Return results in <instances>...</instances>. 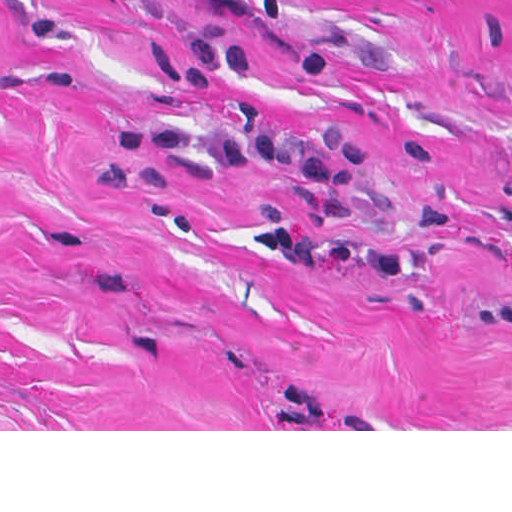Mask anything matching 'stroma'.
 <instances>
[{
	"mask_svg": "<svg viewBox=\"0 0 512 512\" xmlns=\"http://www.w3.org/2000/svg\"><path fill=\"white\" fill-rule=\"evenodd\" d=\"M338 124L398 277L250 254L298 177L117 129ZM0 431H512V0H0Z\"/></svg>",
	"mask_w": 512,
	"mask_h": 512,
	"instance_id": "obj_1",
	"label": "stroma"
}]
</instances>
